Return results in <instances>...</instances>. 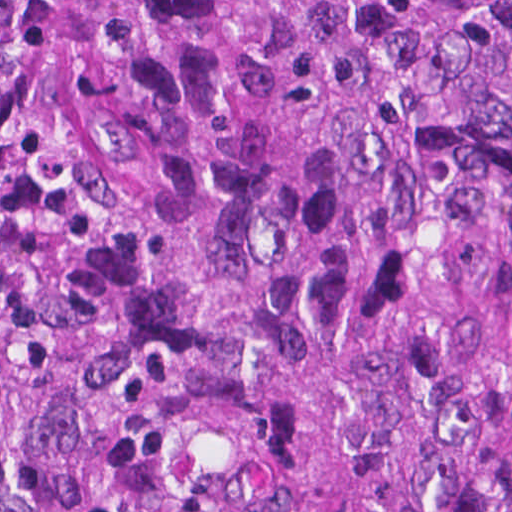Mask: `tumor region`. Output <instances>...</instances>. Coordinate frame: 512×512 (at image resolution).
I'll list each match as a JSON object with an SVG mask.
<instances>
[{
    "label": "tumor region",
    "instance_id": "e687c5a6",
    "mask_svg": "<svg viewBox=\"0 0 512 512\" xmlns=\"http://www.w3.org/2000/svg\"><path fill=\"white\" fill-rule=\"evenodd\" d=\"M0 512H512V0H0Z\"/></svg>",
    "mask_w": 512,
    "mask_h": 512
}]
</instances>
